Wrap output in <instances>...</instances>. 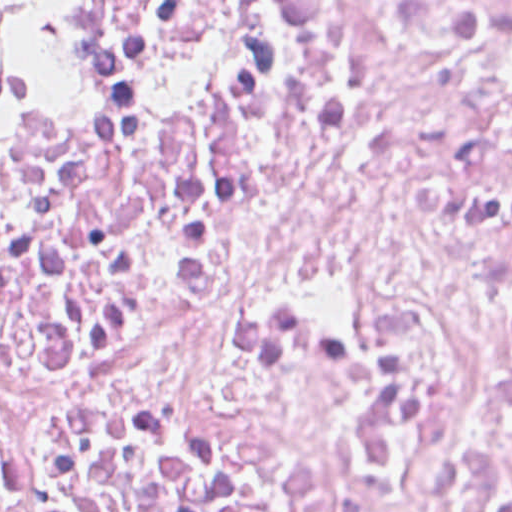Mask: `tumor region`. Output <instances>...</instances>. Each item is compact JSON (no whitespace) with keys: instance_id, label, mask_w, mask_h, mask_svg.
Segmentation results:
<instances>
[{"instance_id":"obj_1","label":"tumor region","mask_w":512,"mask_h":512,"mask_svg":"<svg viewBox=\"0 0 512 512\" xmlns=\"http://www.w3.org/2000/svg\"><path fill=\"white\" fill-rule=\"evenodd\" d=\"M10 96V29L0 11V111L8 104Z\"/></svg>"}]
</instances>
